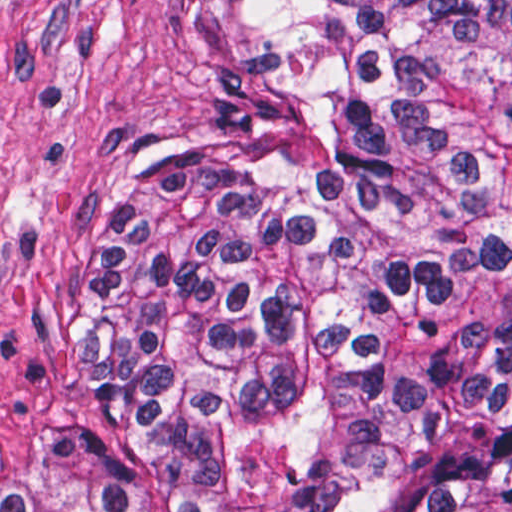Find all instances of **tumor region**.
Returning <instances> with one entry per match:
<instances>
[{
    "instance_id": "obj_1",
    "label": "tumor region",
    "mask_w": 512,
    "mask_h": 512,
    "mask_svg": "<svg viewBox=\"0 0 512 512\" xmlns=\"http://www.w3.org/2000/svg\"><path fill=\"white\" fill-rule=\"evenodd\" d=\"M244 2L305 123L145 134L95 189L0 512H512V0Z\"/></svg>"
}]
</instances>
